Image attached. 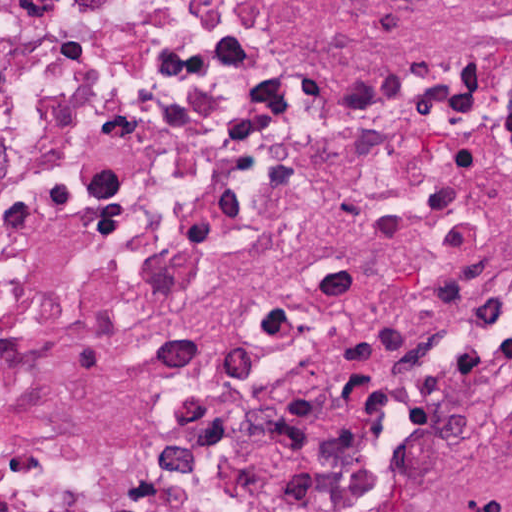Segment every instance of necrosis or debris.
<instances>
[{"label": "necrosis or debris", "instance_id": "4bbe7bcc", "mask_svg": "<svg viewBox=\"0 0 512 512\" xmlns=\"http://www.w3.org/2000/svg\"><path fill=\"white\" fill-rule=\"evenodd\" d=\"M512 343V0H0V512H386Z\"/></svg>", "mask_w": 512, "mask_h": 512}]
</instances>
